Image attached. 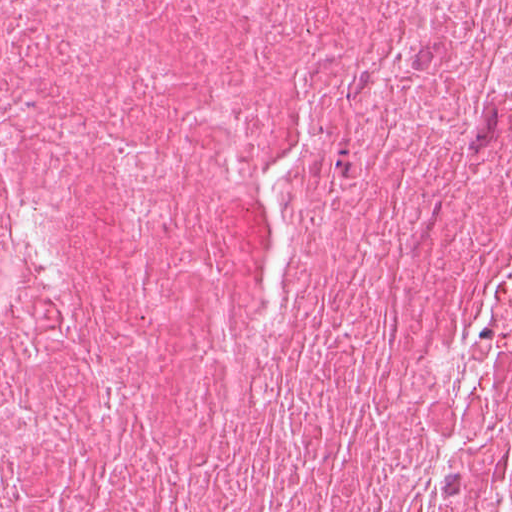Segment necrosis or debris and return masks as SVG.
<instances>
[{
    "label": "necrosis or debris",
    "instance_id": "1",
    "mask_svg": "<svg viewBox=\"0 0 512 512\" xmlns=\"http://www.w3.org/2000/svg\"><path fill=\"white\" fill-rule=\"evenodd\" d=\"M0 512H512V0H0Z\"/></svg>",
    "mask_w": 512,
    "mask_h": 512
}]
</instances>
